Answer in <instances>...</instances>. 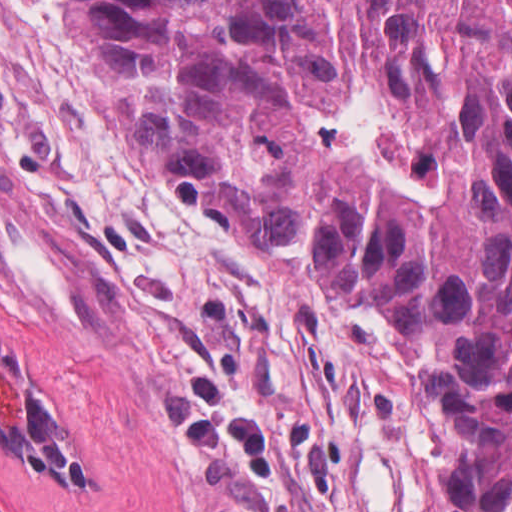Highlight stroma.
I'll use <instances>...</instances> for the list:
<instances>
[{
    "instance_id": "35a3bbf8",
    "label": "stroma",
    "mask_w": 512,
    "mask_h": 512,
    "mask_svg": "<svg viewBox=\"0 0 512 512\" xmlns=\"http://www.w3.org/2000/svg\"><path fill=\"white\" fill-rule=\"evenodd\" d=\"M0 342L91 474L0 435V512H455L405 335L190 202L72 0H0Z\"/></svg>"
}]
</instances>
